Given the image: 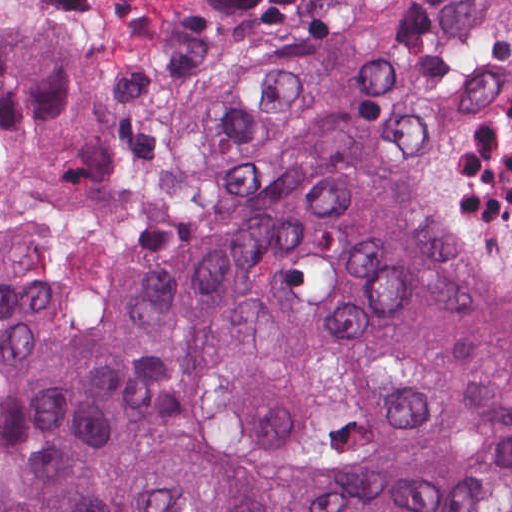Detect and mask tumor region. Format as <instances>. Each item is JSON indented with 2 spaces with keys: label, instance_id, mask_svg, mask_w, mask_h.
<instances>
[{
  "label": "tumor region",
  "instance_id": "tumor-region-1",
  "mask_svg": "<svg viewBox=\"0 0 512 512\" xmlns=\"http://www.w3.org/2000/svg\"><path fill=\"white\" fill-rule=\"evenodd\" d=\"M83 158L51 58L0 40V159ZM0 512H512V274L354 146L254 162L114 335L3 247Z\"/></svg>",
  "mask_w": 512,
  "mask_h": 512
}]
</instances>
